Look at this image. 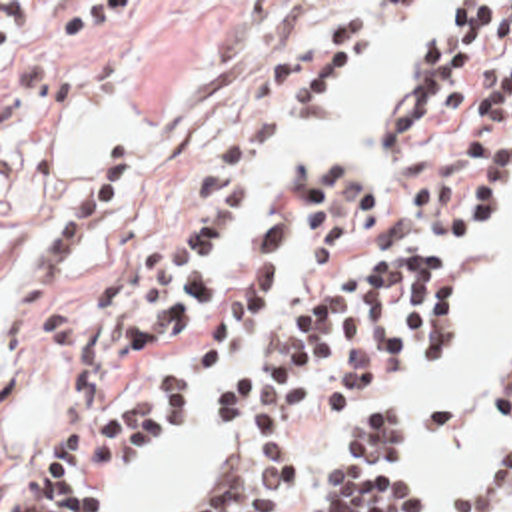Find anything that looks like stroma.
Returning <instances> with one entry per match:
<instances>
[{
  "label": "stroma",
  "mask_w": 512,
  "mask_h": 512,
  "mask_svg": "<svg viewBox=\"0 0 512 512\" xmlns=\"http://www.w3.org/2000/svg\"><path fill=\"white\" fill-rule=\"evenodd\" d=\"M319 2H425V6L403 32L345 66L319 98L284 116L244 174V216L262 194L264 166L274 148L337 84L399 46L401 84L391 90L385 110L409 92L421 68L417 60L419 32L443 22L449 2L512 0H0V512H18L50 437L88 421H110L144 397L154 379L200 339L208 317L242 272L222 270L224 246L236 224L212 254L210 270L218 274L216 286L194 321L172 339L152 347L98 391L76 393V351L46 345L36 321L26 325L22 335H8V304L32 252L98 158L118 142L130 144L134 152L130 192L64 274L50 304L70 308L98 296L120 272L136 244L186 204L196 178L216 150L226 120L262 62L325 20L329 8ZM509 54L505 52L477 70L469 86V110L461 122L449 128L401 146H383L381 112L369 138H337L313 148L347 146L379 166L387 186L385 236L389 242L419 238L437 226L429 214L407 200L405 174L419 162H453L467 154L459 144L461 128L475 112L489 74ZM511 208L512 186L491 208V222L477 242L401 244L417 258L447 264L459 278L457 347L447 363L389 385L337 415L323 417L305 407L301 469L288 491L286 512H315L309 499L315 471L339 457L343 427L373 403L393 401L413 409L417 435L403 467L421 483L419 461L425 455V435L413 401L403 395L439 381L463 361L473 317V288L453 258L487 244L497 220ZM276 220L286 222V300L238 377L258 363L280 321L309 298L296 184ZM481 385H512V379L485 377L475 391V419L483 433L503 449L493 463L459 489L497 465L503 451L512 445L511 427L487 421ZM198 413L218 437L214 451L238 431L236 425L214 417L210 393L166 431L138 467L164 449ZM120 483L88 511L104 512ZM423 491L425 512L455 509L457 491H427L425 487Z\"/></svg>",
  "instance_id": "obj_1"
}]
</instances>
